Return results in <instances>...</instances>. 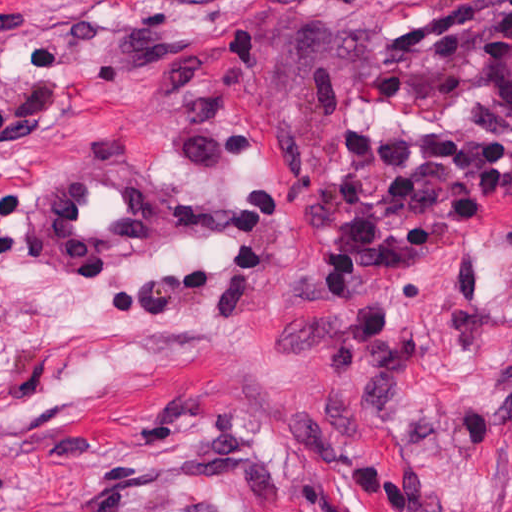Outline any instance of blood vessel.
Segmentation results:
<instances>
[{
	"instance_id": "8fb6f2fc",
	"label": "blood vessel",
	"mask_w": 512,
	"mask_h": 512,
	"mask_svg": "<svg viewBox=\"0 0 512 512\" xmlns=\"http://www.w3.org/2000/svg\"><path fill=\"white\" fill-rule=\"evenodd\" d=\"M171 195L135 160L81 161L44 198L45 261H162Z\"/></svg>"
}]
</instances>
